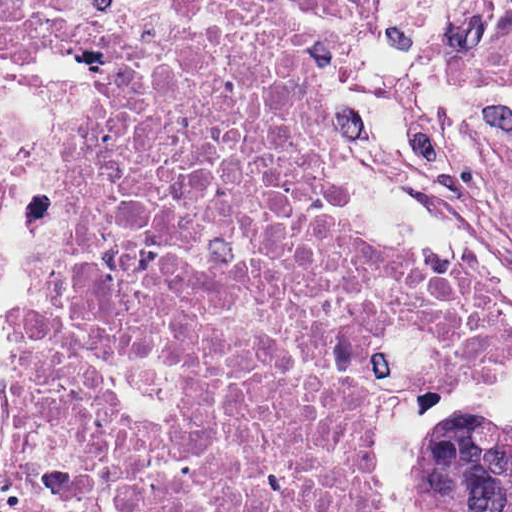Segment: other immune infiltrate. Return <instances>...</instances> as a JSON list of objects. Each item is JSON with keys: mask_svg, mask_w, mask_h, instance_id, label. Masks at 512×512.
<instances>
[{"mask_svg": "<svg viewBox=\"0 0 512 512\" xmlns=\"http://www.w3.org/2000/svg\"><path fill=\"white\" fill-rule=\"evenodd\" d=\"M67 129L68 97L59 82L0 34V288Z\"/></svg>", "mask_w": 512, "mask_h": 512, "instance_id": "1", "label": "other immune infiltrate"}]
</instances>
